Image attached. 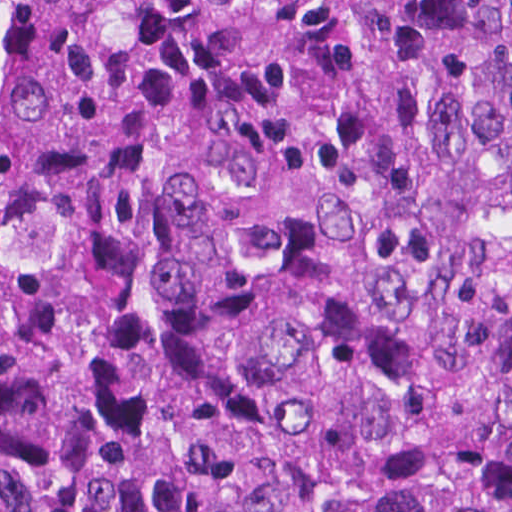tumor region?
<instances>
[{"label": "tumor region", "instance_id": "obj_1", "mask_svg": "<svg viewBox=\"0 0 512 512\" xmlns=\"http://www.w3.org/2000/svg\"><path fill=\"white\" fill-rule=\"evenodd\" d=\"M0 512H512V0H0Z\"/></svg>", "mask_w": 512, "mask_h": 512}]
</instances>
